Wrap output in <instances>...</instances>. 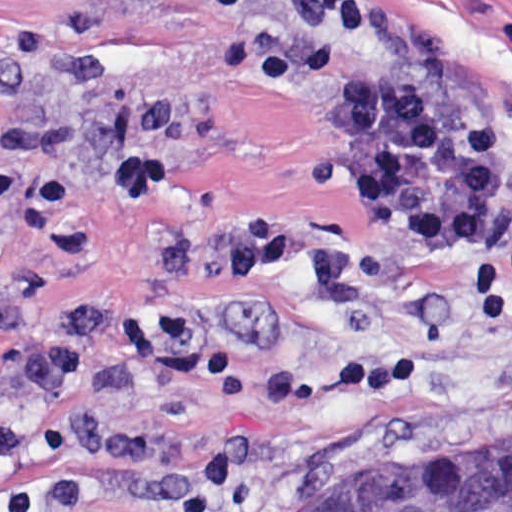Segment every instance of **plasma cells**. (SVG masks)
Segmentation results:
<instances>
[{"mask_svg": "<svg viewBox=\"0 0 512 512\" xmlns=\"http://www.w3.org/2000/svg\"><path fill=\"white\" fill-rule=\"evenodd\" d=\"M334 12L335 0H288L283 34L258 54L251 79L263 89L303 90L321 116L332 182L358 212L417 252L467 256L483 249L494 205L511 180L504 126L308 42ZM175 111L163 93L140 101V142L110 177L126 204L149 202L173 174L165 143ZM364 249L358 236L324 223L246 215L210 240L166 243L153 257L173 280L205 288L232 287L287 261L308 260L329 297L367 301L369 284L355 261ZM109 318V310H84L62 335L50 337L24 310L0 302V332L22 329L14 364L31 399L60 400L83 374L84 349Z\"/></svg>", "mask_w": 512, "mask_h": 512, "instance_id": "1", "label": "plasma cells"}]
</instances>
